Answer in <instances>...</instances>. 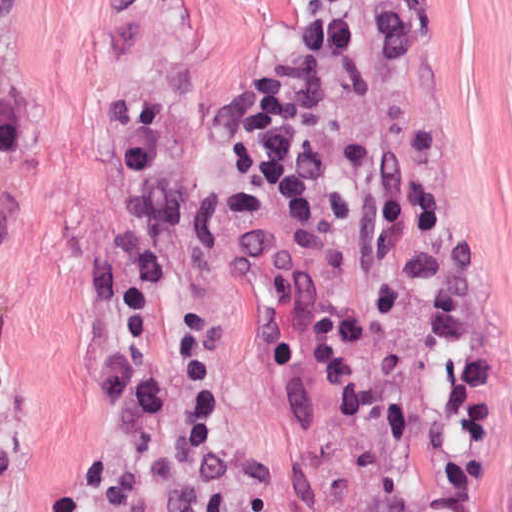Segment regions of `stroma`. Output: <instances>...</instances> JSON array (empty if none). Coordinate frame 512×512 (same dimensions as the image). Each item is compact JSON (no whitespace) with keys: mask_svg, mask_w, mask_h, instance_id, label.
<instances>
[{"mask_svg":"<svg viewBox=\"0 0 512 512\" xmlns=\"http://www.w3.org/2000/svg\"><path fill=\"white\" fill-rule=\"evenodd\" d=\"M418 102L512 328V0H310ZM23 154L0 157V512H54L121 309L88 289L121 231L113 97L164 104L151 300L263 512H392L277 288L262 129L277 0H0Z\"/></svg>","mask_w":512,"mask_h":512,"instance_id":"stroma-1","label":"stroma"}]
</instances>
